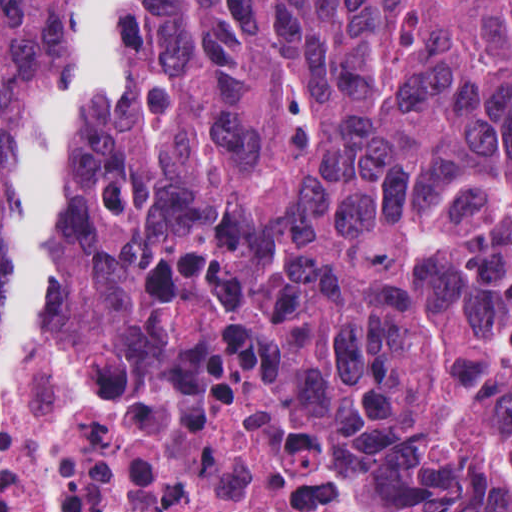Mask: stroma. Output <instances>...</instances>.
Returning a JSON list of instances; mask_svg holds the SVG:
<instances>
[{
  "instance_id": "stroma-1",
  "label": "stroma",
  "mask_w": 512,
  "mask_h": 512,
  "mask_svg": "<svg viewBox=\"0 0 512 512\" xmlns=\"http://www.w3.org/2000/svg\"><path fill=\"white\" fill-rule=\"evenodd\" d=\"M49 4L0 0V223Z\"/></svg>"
}]
</instances>
